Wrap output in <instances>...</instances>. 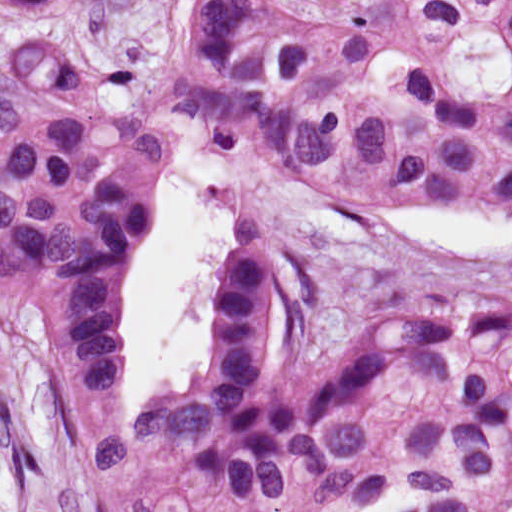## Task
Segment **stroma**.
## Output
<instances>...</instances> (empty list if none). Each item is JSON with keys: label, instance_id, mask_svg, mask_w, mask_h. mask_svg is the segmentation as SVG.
<instances>
[{"label": "stroma", "instance_id": "obj_1", "mask_svg": "<svg viewBox=\"0 0 512 512\" xmlns=\"http://www.w3.org/2000/svg\"><path fill=\"white\" fill-rule=\"evenodd\" d=\"M130 1L54 0L29 10L0 4V46L33 27H59L86 39H103L125 23ZM28 87L0 63V93ZM179 146L155 168L136 254L156 221ZM203 156L231 198L227 250L243 238L258 241L284 275L290 376L308 377L336 367L357 338L389 321L442 318L512 332V239L474 256L423 250L375 222L352 225L322 212L252 158ZM459 205L512 214L505 207ZM43 312L36 280L19 285L0 309V512H84L65 454L34 397ZM121 347L122 389L125 318Z\"/></svg>", "mask_w": 512, "mask_h": 512}]
</instances>
